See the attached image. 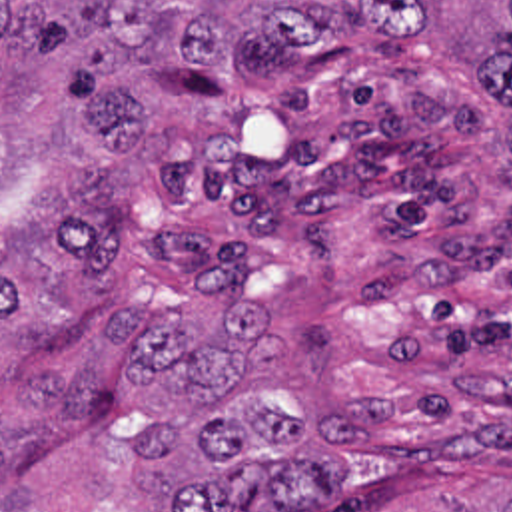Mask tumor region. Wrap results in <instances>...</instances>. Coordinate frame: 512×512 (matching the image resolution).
<instances>
[{"mask_svg": "<svg viewBox=\"0 0 512 512\" xmlns=\"http://www.w3.org/2000/svg\"><path fill=\"white\" fill-rule=\"evenodd\" d=\"M353 32L425 38L512 108V0H0V50L64 52L100 150L42 186L34 236L40 146L0 118V512H373L423 455L417 381L357 399L293 379L281 320L323 244L311 196L220 168L170 208L162 258L110 222L126 158L168 144L130 66L271 86L339 64ZM439 512H512V475Z\"/></svg>", "mask_w": 512, "mask_h": 512, "instance_id": "tumor-region-1", "label": "tumor region"}]
</instances>
